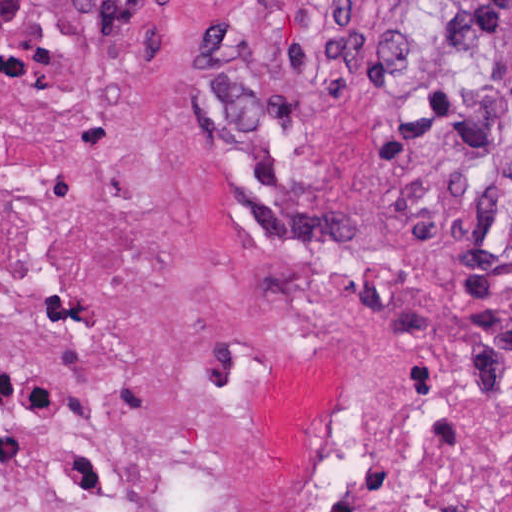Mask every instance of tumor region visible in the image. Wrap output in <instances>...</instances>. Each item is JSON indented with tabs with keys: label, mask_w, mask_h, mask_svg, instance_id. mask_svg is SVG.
I'll use <instances>...</instances> for the list:
<instances>
[{
	"label": "tumor region",
	"mask_w": 512,
	"mask_h": 512,
	"mask_svg": "<svg viewBox=\"0 0 512 512\" xmlns=\"http://www.w3.org/2000/svg\"><path fill=\"white\" fill-rule=\"evenodd\" d=\"M352 44L363 65L460 80L478 124L469 169L512 186V0H431Z\"/></svg>",
	"instance_id": "tumor-region-1"
}]
</instances>
